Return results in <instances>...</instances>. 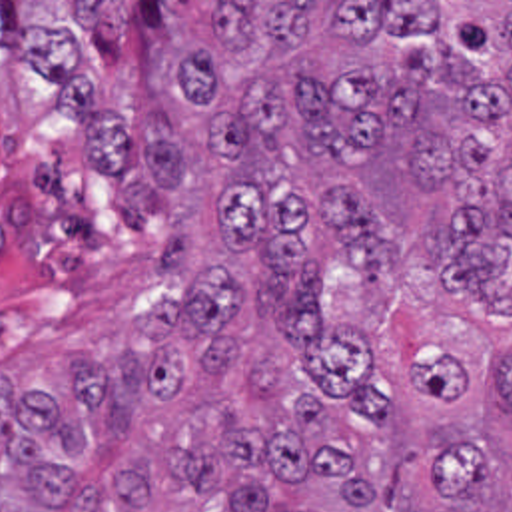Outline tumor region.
Returning <instances> with one entry per match:
<instances>
[{"label": "tumor region", "mask_w": 512, "mask_h": 512, "mask_svg": "<svg viewBox=\"0 0 512 512\" xmlns=\"http://www.w3.org/2000/svg\"><path fill=\"white\" fill-rule=\"evenodd\" d=\"M145 142L121 2L0 40V512H512L489 381L327 270L423 242L512 307V2H169Z\"/></svg>", "instance_id": "obj_1"}]
</instances>
